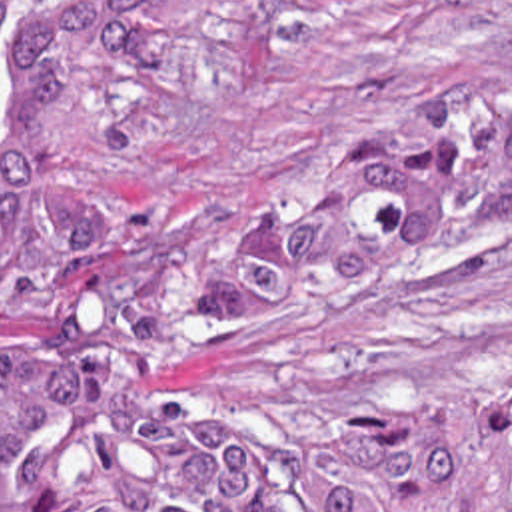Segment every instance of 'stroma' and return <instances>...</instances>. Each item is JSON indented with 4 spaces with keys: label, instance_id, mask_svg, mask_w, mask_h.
I'll return each mask as SVG.
<instances>
[{
    "label": "stroma",
    "instance_id": "obj_1",
    "mask_svg": "<svg viewBox=\"0 0 512 512\" xmlns=\"http://www.w3.org/2000/svg\"><path fill=\"white\" fill-rule=\"evenodd\" d=\"M510 102L512 0H206L172 28L101 38L81 70V164L128 212L232 216L434 110ZM43 304L0 280V352ZM484 390H512V226L274 340L190 354L142 398L370 438L422 398Z\"/></svg>",
    "mask_w": 512,
    "mask_h": 512
}]
</instances>
